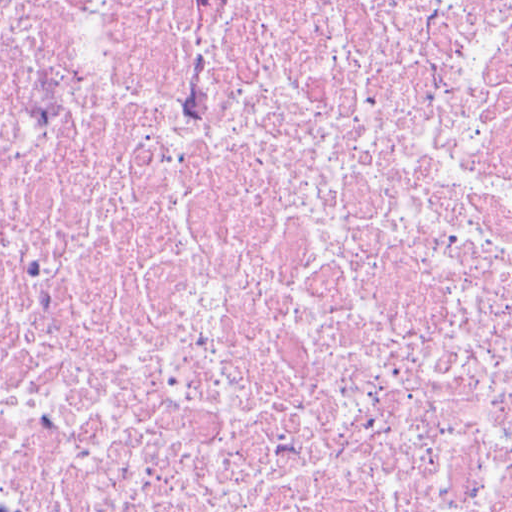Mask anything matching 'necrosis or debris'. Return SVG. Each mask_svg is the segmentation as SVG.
Here are the masks:
<instances>
[{"instance_id":"obj_1","label":"necrosis or debris","mask_w":512,"mask_h":512,"mask_svg":"<svg viewBox=\"0 0 512 512\" xmlns=\"http://www.w3.org/2000/svg\"><path fill=\"white\" fill-rule=\"evenodd\" d=\"M0 512H512V0H0Z\"/></svg>"}]
</instances>
